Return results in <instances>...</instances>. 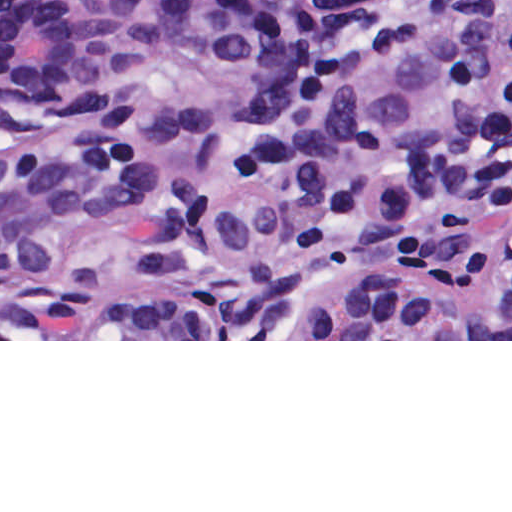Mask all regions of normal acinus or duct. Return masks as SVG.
Wrapping results in <instances>:
<instances>
[{
	"mask_svg": "<svg viewBox=\"0 0 512 512\" xmlns=\"http://www.w3.org/2000/svg\"><path fill=\"white\" fill-rule=\"evenodd\" d=\"M1 339H512L466 0H1Z\"/></svg>",
	"mask_w": 512,
	"mask_h": 512,
	"instance_id": "1",
	"label": "normal acinus or duct"
}]
</instances>
